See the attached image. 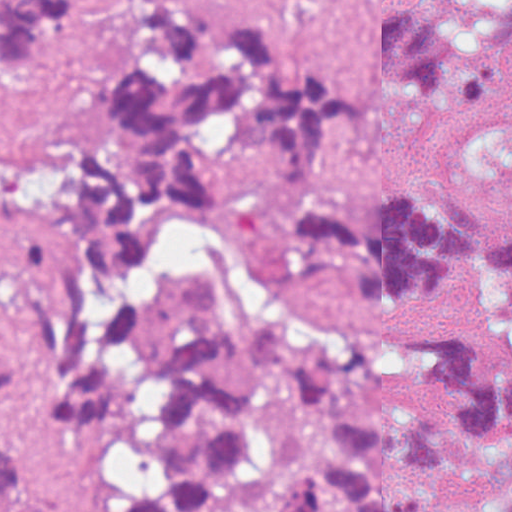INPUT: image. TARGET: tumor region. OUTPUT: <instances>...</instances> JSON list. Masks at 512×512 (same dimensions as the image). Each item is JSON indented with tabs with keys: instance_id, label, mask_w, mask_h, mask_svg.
Returning a JSON list of instances; mask_svg holds the SVG:
<instances>
[{
	"instance_id": "1",
	"label": "tumor region",
	"mask_w": 512,
	"mask_h": 512,
	"mask_svg": "<svg viewBox=\"0 0 512 512\" xmlns=\"http://www.w3.org/2000/svg\"><path fill=\"white\" fill-rule=\"evenodd\" d=\"M103 18L107 78L69 76ZM511 27L512 0L370 9L366 55L393 95L472 105ZM50 74L82 108L30 180L40 238L0 255V405L65 385L61 422L102 425L152 381L158 479L123 512H512V369L443 319L512 260V221H482L453 181L333 199L365 89L307 44L296 0H0V78ZM245 165L302 254L419 318L298 357L287 313H234L204 258L179 284L189 331L149 346L130 306L145 270L179 224L237 204ZM21 478L0 450V501Z\"/></svg>"
}]
</instances>
